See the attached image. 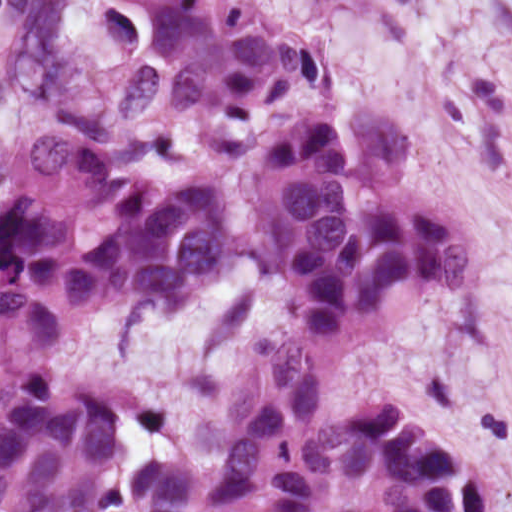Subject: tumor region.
<instances>
[{"label":"tumor region","mask_w":512,"mask_h":512,"mask_svg":"<svg viewBox=\"0 0 512 512\" xmlns=\"http://www.w3.org/2000/svg\"><path fill=\"white\" fill-rule=\"evenodd\" d=\"M146 9V57L118 92L138 127H255L324 87L316 43L257 0H121ZM0 189V512H480L460 448L385 399L322 415L344 350L430 290L464 284V231L393 185L405 137L384 100L324 97L281 112L250 151L238 226L284 281L294 327L245 433L216 464L122 444L115 403L52 374L62 340L112 309L179 313L231 265L235 203L211 180L142 176L55 115Z\"/></svg>","instance_id":"tumor-region-1"}]
</instances>
